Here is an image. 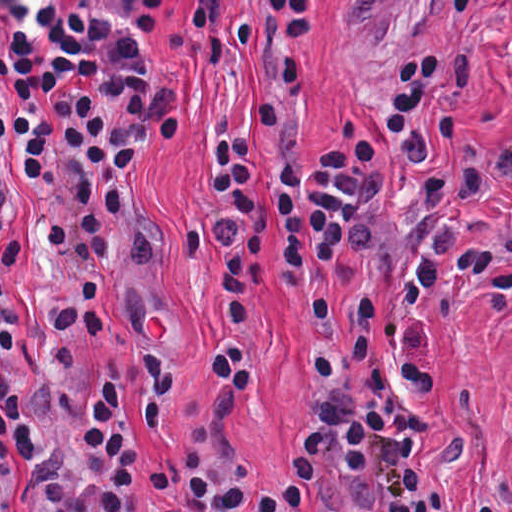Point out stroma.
Segmentation results:
<instances>
[{
    "instance_id": "obj_1",
    "label": "stroma",
    "mask_w": 512,
    "mask_h": 512,
    "mask_svg": "<svg viewBox=\"0 0 512 512\" xmlns=\"http://www.w3.org/2000/svg\"><path fill=\"white\" fill-rule=\"evenodd\" d=\"M425 334L437 369V431L418 451L465 504L512 502V306L427 312ZM248 336L259 381L251 400L232 411V435L245 449L262 466H282L304 428L331 422L318 390V316L303 297L170 355L180 363V406L159 427L149 428L144 411L145 367L128 374L125 410L143 467L140 512H188L159 488V472L187 449L223 392L215 351ZM10 512H44L19 451Z\"/></svg>"
}]
</instances>
